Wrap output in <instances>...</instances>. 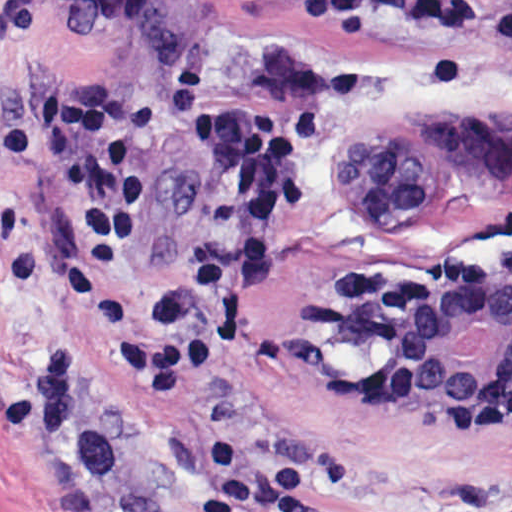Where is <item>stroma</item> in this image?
Returning <instances> with one entry per match:
<instances>
[{"instance_id": "35a3bbf8", "label": "stroma", "mask_w": 512, "mask_h": 512, "mask_svg": "<svg viewBox=\"0 0 512 512\" xmlns=\"http://www.w3.org/2000/svg\"><path fill=\"white\" fill-rule=\"evenodd\" d=\"M464 26L328 24L285 0H0V132L61 85L126 93L185 65L230 100L320 117L311 193L258 307L185 383L142 374L157 291L231 241L223 175L158 122L145 245L87 283L70 201L0 168V512H201L208 442L305 478L317 512H512V394L409 420L332 343L328 294L378 275L451 287L512 263V0Z\"/></svg>"}]
</instances>
